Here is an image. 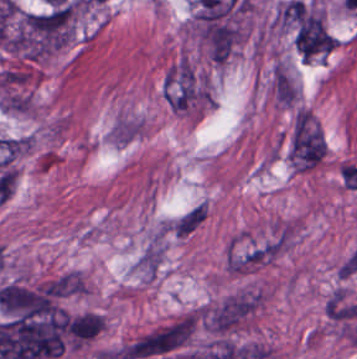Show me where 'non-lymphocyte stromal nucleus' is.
<instances>
[{
	"label": "non-lymphocyte stromal nucleus",
	"instance_id": "dd21d789",
	"mask_svg": "<svg viewBox=\"0 0 357 359\" xmlns=\"http://www.w3.org/2000/svg\"><path fill=\"white\" fill-rule=\"evenodd\" d=\"M192 326L189 316L172 319L155 327L123 347L125 359L165 356L186 343Z\"/></svg>",
	"mask_w": 357,
	"mask_h": 359
},
{
	"label": "non-lymphocyte stromal nucleus",
	"instance_id": "a72fc3eb",
	"mask_svg": "<svg viewBox=\"0 0 357 359\" xmlns=\"http://www.w3.org/2000/svg\"><path fill=\"white\" fill-rule=\"evenodd\" d=\"M323 137L321 130L301 108L296 111L288 145V158L295 169L307 170L321 162Z\"/></svg>",
	"mask_w": 357,
	"mask_h": 359
},
{
	"label": "non-lymphocyte stromal nucleus",
	"instance_id": "3746e769",
	"mask_svg": "<svg viewBox=\"0 0 357 359\" xmlns=\"http://www.w3.org/2000/svg\"><path fill=\"white\" fill-rule=\"evenodd\" d=\"M258 304L256 294H231L202 313L207 330L229 333L237 328Z\"/></svg>",
	"mask_w": 357,
	"mask_h": 359
},
{
	"label": "non-lymphocyte stromal nucleus",
	"instance_id": "fc2b8d12",
	"mask_svg": "<svg viewBox=\"0 0 357 359\" xmlns=\"http://www.w3.org/2000/svg\"><path fill=\"white\" fill-rule=\"evenodd\" d=\"M206 215V203L198 200L166 220L162 224V231L183 240L204 221Z\"/></svg>",
	"mask_w": 357,
	"mask_h": 359
},
{
	"label": "non-lymphocyte stromal nucleus",
	"instance_id": "81446118",
	"mask_svg": "<svg viewBox=\"0 0 357 359\" xmlns=\"http://www.w3.org/2000/svg\"><path fill=\"white\" fill-rule=\"evenodd\" d=\"M144 121L131 113H118L108 127L107 142L126 147L142 135Z\"/></svg>",
	"mask_w": 357,
	"mask_h": 359
}]
</instances>
